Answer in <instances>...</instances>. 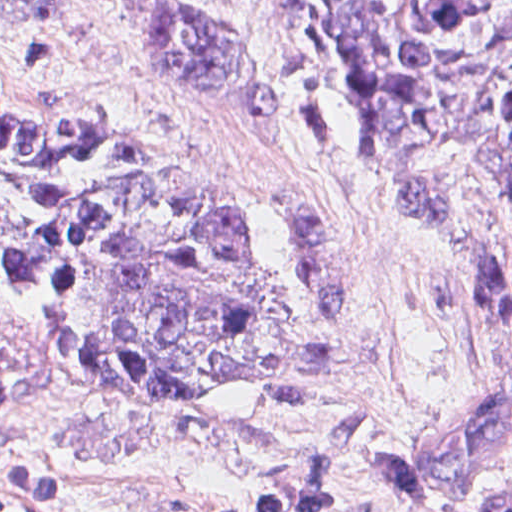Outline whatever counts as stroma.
I'll list each match as a JSON object with an SVG mask.
<instances>
[{
	"label": "stroma",
	"mask_w": 512,
	"mask_h": 512,
	"mask_svg": "<svg viewBox=\"0 0 512 512\" xmlns=\"http://www.w3.org/2000/svg\"><path fill=\"white\" fill-rule=\"evenodd\" d=\"M185 1L265 55L270 120L157 87L126 0H53L44 31H0V91L260 207L292 262L289 357L200 396L108 387L69 368L43 293L0 292V512H489L512 453L428 502L408 500L406 462L451 407L512 385V200L444 147L363 151L288 0Z\"/></svg>",
	"instance_id": "35a3bbf8"
}]
</instances>
